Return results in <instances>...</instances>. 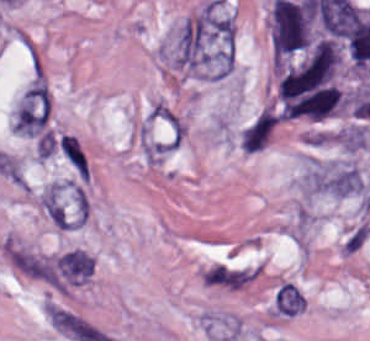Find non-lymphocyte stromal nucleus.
<instances>
[{"label": "non-lymphocyte stromal nucleus", "instance_id": "obj_1", "mask_svg": "<svg viewBox=\"0 0 370 341\" xmlns=\"http://www.w3.org/2000/svg\"><path fill=\"white\" fill-rule=\"evenodd\" d=\"M1 251L10 266L20 274L57 285V256L14 236L2 240Z\"/></svg>", "mask_w": 370, "mask_h": 341}, {"label": "non-lymphocyte stromal nucleus", "instance_id": "obj_2", "mask_svg": "<svg viewBox=\"0 0 370 341\" xmlns=\"http://www.w3.org/2000/svg\"><path fill=\"white\" fill-rule=\"evenodd\" d=\"M14 120L23 136L39 137L46 133L49 123V91L39 75L24 93Z\"/></svg>", "mask_w": 370, "mask_h": 341}, {"label": "non-lymphocyte stromal nucleus", "instance_id": "obj_3", "mask_svg": "<svg viewBox=\"0 0 370 341\" xmlns=\"http://www.w3.org/2000/svg\"><path fill=\"white\" fill-rule=\"evenodd\" d=\"M46 318L69 341H113L87 317L61 305L48 302Z\"/></svg>", "mask_w": 370, "mask_h": 341}, {"label": "non-lymphocyte stromal nucleus", "instance_id": "obj_4", "mask_svg": "<svg viewBox=\"0 0 370 341\" xmlns=\"http://www.w3.org/2000/svg\"><path fill=\"white\" fill-rule=\"evenodd\" d=\"M260 274L257 264L215 262L202 268L203 284L239 290Z\"/></svg>", "mask_w": 370, "mask_h": 341}, {"label": "non-lymphocyte stromal nucleus", "instance_id": "obj_5", "mask_svg": "<svg viewBox=\"0 0 370 341\" xmlns=\"http://www.w3.org/2000/svg\"><path fill=\"white\" fill-rule=\"evenodd\" d=\"M63 276L71 280H87L95 267L94 258L78 249H71L56 258Z\"/></svg>", "mask_w": 370, "mask_h": 341}, {"label": "non-lymphocyte stromal nucleus", "instance_id": "obj_6", "mask_svg": "<svg viewBox=\"0 0 370 341\" xmlns=\"http://www.w3.org/2000/svg\"><path fill=\"white\" fill-rule=\"evenodd\" d=\"M370 235V225L366 222H359L350 228L343 238L339 250L342 257H352L368 241Z\"/></svg>", "mask_w": 370, "mask_h": 341}, {"label": "non-lymphocyte stromal nucleus", "instance_id": "obj_7", "mask_svg": "<svg viewBox=\"0 0 370 341\" xmlns=\"http://www.w3.org/2000/svg\"><path fill=\"white\" fill-rule=\"evenodd\" d=\"M61 150L76 168L80 175L87 179L84 157L76 136L62 135Z\"/></svg>", "mask_w": 370, "mask_h": 341}]
</instances>
